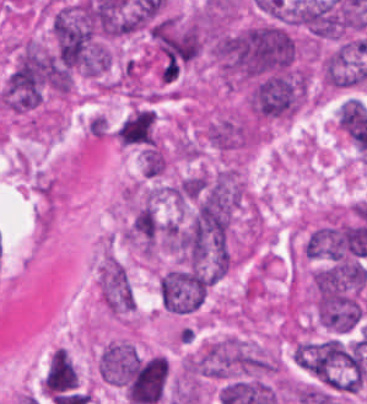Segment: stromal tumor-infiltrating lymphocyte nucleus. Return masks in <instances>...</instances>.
Wrapping results in <instances>:
<instances>
[{
    "instance_id": "obj_1",
    "label": "stromal tumor-infiltrating lymphocyte nucleus",
    "mask_w": 367,
    "mask_h": 404,
    "mask_svg": "<svg viewBox=\"0 0 367 404\" xmlns=\"http://www.w3.org/2000/svg\"><path fill=\"white\" fill-rule=\"evenodd\" d=\"M76 383L77 370L67 350L56 348L48 358L43 375L44 392L54 396L75 387Z\"/></svg>"
}]
</instances>
